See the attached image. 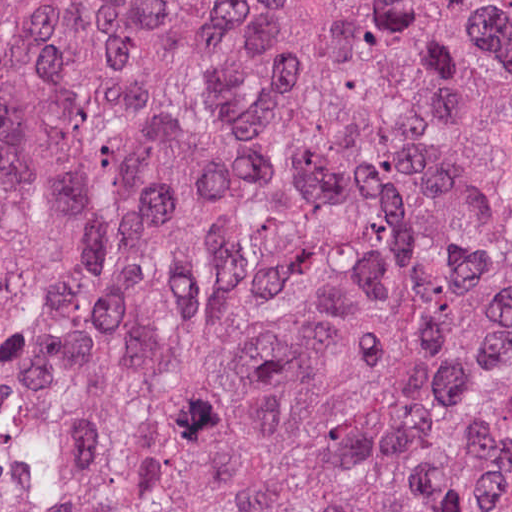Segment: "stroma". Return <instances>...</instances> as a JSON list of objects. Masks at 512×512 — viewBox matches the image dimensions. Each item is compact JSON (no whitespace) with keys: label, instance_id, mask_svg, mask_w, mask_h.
Segmentation results:
<instances>
[{"label":"stroma","instance_id":"1","mask_svg":"<svg viewBox=\"0 0 512 512\" xmlns=\"http://www.w3.org/2000/svg\"><path fill=\"white\" fill-rule=\"evenodd\" d=\"M491 325L512 386V215L491 282Z\"/></svg>","mask_w":512,"mask_h":512}]
</instances>
